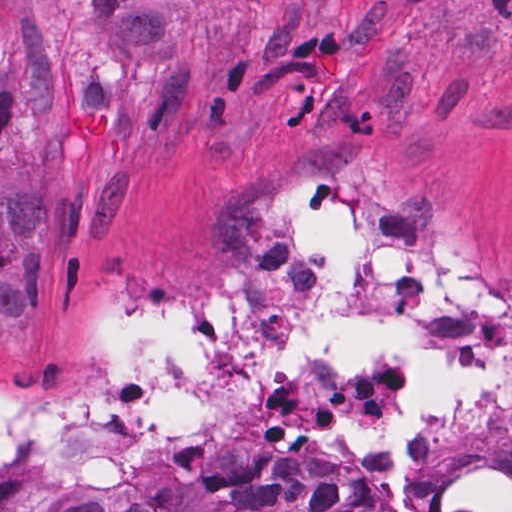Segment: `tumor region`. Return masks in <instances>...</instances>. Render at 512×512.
<instances>
[{
    "label": "tumor region",
    "mask_w": 512,
    "mask_h": 512,
    "mask_svg": "<svg viewBox=\"0 0 512 512\" xmlns=\"http://www.w3.org/2000/svg\"><path fill=\"white\" fill-rule=\"evenodd\" d=\"M128 120L113 109L79 108L67 119L65 160L75 170H95L105 144L123 139Z\"/></svg>",
    "instance_id": "obj_1"
}]
</instances>
